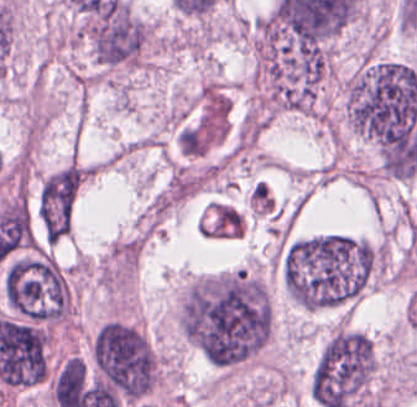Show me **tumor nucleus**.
Masks as SVG:
<instances>
[{
  "label": "tumor nucleus",
  "mask_w": 417,
  "mask_h": 407,
  "mask_svg": "<svg viewBox=\"0 0 417 407\" xmlns=\"http://www.w3.org/2000/svg\"><path fill=\"white\" fill-rule=\"evenodd\" d=\"M88 354L129 404L153 394L161 384L155 347L135 323L106 320L96 328Z\"/></svg>",
  "instance_id": "2"
},
{
  "label": "tumor nucleus",
  "mask_w": 417,
  "mask_h": 407,
  "mask_svg": "<svg viewBox=\"0 0 417 407\" xmlns=\"http://www.w3.org/2000/svg\"><path fill=\"white\" fill-rule=\"evenodd\" d=\"M1 299L23 319L71 321L76 295L67 270L49 253L21 252L3 273Z\"/></svg>",
  "instance_id": "1"
}]
</instances>
